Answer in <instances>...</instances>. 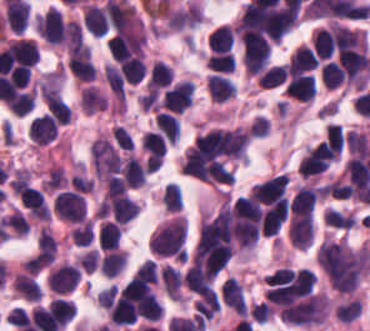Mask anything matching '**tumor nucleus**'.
I'll return each mask as SVG.
<instances>
[{"label": "tumor nucleus", "mask_w": 370, "mask_h": 331, "mask_svg": "<svg viewBox=\"0 0 370 331\" xmlns=\"http://www.w3.org/2000/svg\"><path fill=\"white\" fill-rule=\"evenodd\" d=\"M287 236L293 248L306 250L313 241L312 217L291 216Z\"/></svg>", "instance_id": "8643909e"}, {"label": "tumor nucleus", "mask_w": 370, "mask_h": 331, "mask_svg": "<svg viewBox=\"0 0 370 331\" xmlns=\"http://www.w3.org/2000/svg\"><path fill=\"white\" fill-rule=\"evenodd\" d=\"M317 256L331 287L342 293L356 290L370 268L368 243L326 238Z\"/></svg>", "instance_id": "2f306a5c"}]
</instances>
